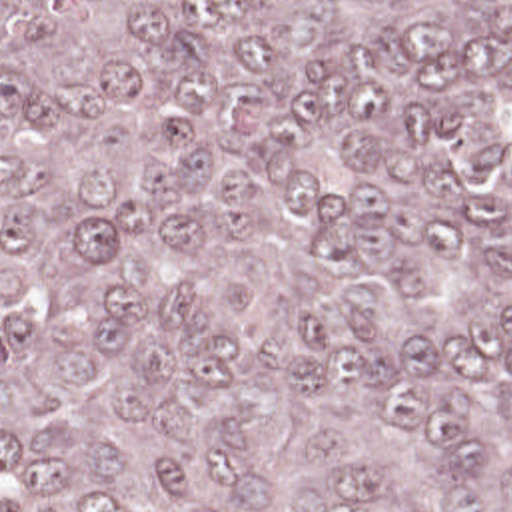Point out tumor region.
I'll return each mask as SVG.
<instances>
[{
  "label": "tumor region",
  "instance_id": "obj_1",
  "mask_svg": "<svg viewBox=\"0 0 512 512\" xmlns=\"http://www.w3.org/2000/svg\"><path fill=\"white\" fill-rule=\"evenodd\" d=\"M0 512H512V0H0Z\"/></svg>",
  "mask_w": 512,
  "mask_h": 512
}]
</instances>
